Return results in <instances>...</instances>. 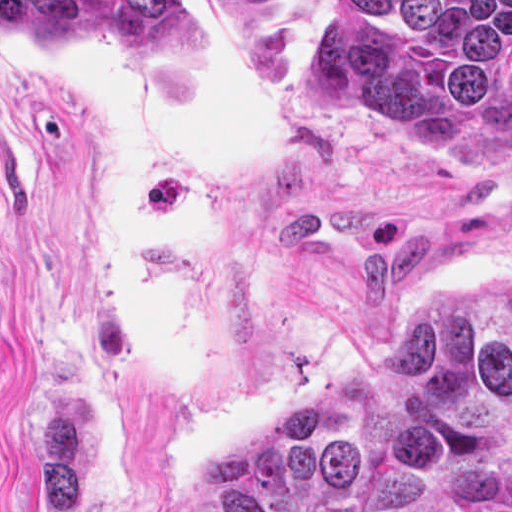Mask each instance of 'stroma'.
I'll list each match as a JSON object with an SVG mask.
<instances>
[{
	"label": "stroma",
	"instance_id": "stroma-1",
	"mask_svg": "<svg viewBox=\"0 0 512 512\" xmlns=\"http://www.w3.org/2000/svg\"><path fill=\"white\" fill-rule=\"evenodd\" d=\"M325 1L512 0H0V27L240 49L304 129L220 193L196 359L159 387L83 251L86 116L0 48V512H178L422 297L512 274V129L396 141L308 109L292 68Z\"/></svg>",
	"mask_w": 512,
	"mask_h": 512
}]
</instances>
